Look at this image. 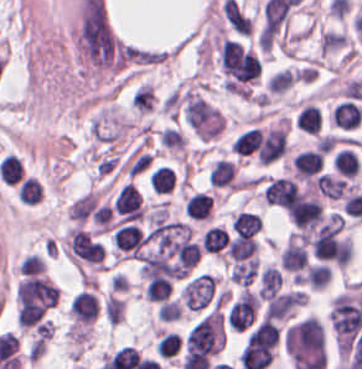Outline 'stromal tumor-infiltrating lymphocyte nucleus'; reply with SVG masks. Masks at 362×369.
<instances>
[{"instance_id":"obj_19","label":"stromal tumor-infiltrating lymphocyte nucleus","mask_w":362,"mask_h":369,"mask_svg":"<svg viewBox=\"0 0 362 369\" xmlns=\"http://www.w3.org/2000/svg\"><path fill=\"white\" fill-rule=\"evenodd\" d=\"M331 277L330 267L324 263L309 266L305 275L306 284L310 289L320 290L325 287Z\"/></svg>"},{"instance_id":"obj_18","label":"stromal tumor-infiltrating lymphocyte nucleus","mask_w":362,"mask_h":369,"mask_svg":"<svg viewBox=\"0 0 362 369\" xmlns=\"http://www.w3.org/2000/svg\"><path fill=\"white\" fill-rule=\"evenodd\" d=\"M174 181L171 169L166 166H159L149 179L151 190L161 195L171 190Z\"/></svg>"},{"instance_id":"obj_10","label":"stromal tumor-infiltrating lymphocyte nucleus","mask_w":362,"mask_h":369,"mask_svg":"<svg viewBox=\"0 0 362 369\" xmlns=\"http://www.w3.org/2000/svg\"><path fill=\"white\" fill-rule=\"evenodd\" d=\"M331 164L335 173L354 177L359 171L358 157L356 152L349 147H342L332 158Z\"/></svg>"},{"instance_id":"obj_9","label":"stromal tumor-infiltrating lymphocyte nucleus","mask_w":362,"mask_h":369,"mask_svg":"<svg viewBox=\"0 0 362 369\" xmlns=\"http://www.w3.org/2000/svg\"><path fill=\"white\" fill-rule=\"evenodd\" d=\"M228 234L227 231L219 227L212 226L207 228L200 240L202 252L213 256H221L227 247Z\"/></svg>"},{"instance_id":"obj_5","label":"stromal tumor-infiltrating lymphocyte nucleus","mask_w":362,"mask_h":369,"mask_svg":"<svg viewBox=\"0 0 362 369\" xmlns=\"http://www.w3.org/2000/svg\"><path fill=\"white\" fill-rule=\"evenodd\" d=\"M290 167L294 177L312 178L322 169L321 156L317 149H304L294 154Z\"/></svg>"},{"instance_id":"obj_3","label":"stromal tumor-infiltrating lymphocyte nucleus","mask_w":362,"mask_h":369,"mask_svg":"<svg viewBox=\"0 0 362 369\" xmlns=\"http://www.w3.org/2000/svg\"><path fill=\"white\" fill-rule=\"evenodd\" d=\"M208 185L213 188L238 189L237 164L218 159L208 171Z\"/></svg>"},{"instance_id":"obj_8","label":"stromal tumor-infiltrating lymphocyte nucleus","mask_w":362,"mask_h":369,"mask_svg":"<svg viewBox=\"0 0 362 369\" xmlns=\"http://www.w3.org/2000/svg\"><path fill=\"white\" fill-rule=\"evenodd\" d=\"M281 275L273 265H265L258 276V298L269 300L278 293Z\"/></svg>"},{"instance_id":"obj_13","label":"stromal tumor-infiltrating lymphocyte nucleus","mask_w":362,"mask_h":369,"mask_svg":"<svg viewBox=\"0 0 362 369\" xmlns=\"http://www.w3.org/2000/svg\"><path fill=\"white\" fill-rule=\"evenodd\" d=\"M258 248L259 245L253 238L237 236L229 240L226 253L229 258L238 262L253 256Z\"/></svg>"},{"instance_id":"obj_1","label":"stromal tumor-infiltrating lymphocyte nucleus","mask_w":362,"mask_h":369,"mask_svg":"<svg viewBox=\"0 0 362 369\" xmlns=\"http://www.w3.org/2000/svg\"><path fill=\"white\" fill-rule=\"evenodd\" d=\"M145 242L142 232L134 224H120L110 235V243L114 249L125 256L134 258Z\"/></svg>"},{"instance_id":"obj_16","label":"stromal tumor-infiltrating lymphocyte nucleus","mask_w":362,"mask_h":369,"mask_svg":"<svg viewBox=\"0 0 362 369\" xmlns=\"http://www.w3.org/2000/svg\"><path fill=\"white\" fill-rule=\"evenodd\" d=\"M171 294V282L163 277H150L145 288V301L162 302Z\"/></svg>"},{"instance_id":"obj_7","label":"stromal tumor-infiltrating lymphocyte nucleus","mask_w":362,"mask_h":369,"mask_svg":"<svg viewBox=\"0 0 362 369\" xmlns=\"http://www.w3.org/2000/svg\"><path fill=\"white\" fill-rule=\"evenodd\" d=\"M184 212L191 219L209 220L212 213L211 194L196 192L185 201Z\"/></svg>"},{"instance_id":"obj_4","label":"stromal tumor-infiltrating lymphocyte nucleus","mask_w":362,"mask_h":369,"mask_svg":"<svg viewBox=\"0 0 362 369\" xmlns=\"http://www.w3.org/2000/svg\"><path fill=\"white\" fill-rule=\"evenodd\" d=\"M279 261L286 272L297 273L304 270L307 256L302 243L288 236L280 251Z\"/></svg>"},{"instance_id":"obj_17","label":"stromal tumor-infiltrating lymphocyte nucleus","mask_w":362,"mask_h":369,"mask_svg":"<svg viewBox=\"0 0 362 369\" xmlns=\"http://www.w3.org/2000/svg\"><path fill=\"white\" fill-rule=\"evenodd\" d=\"M260 130L261 128L254 126L237 136L231 145L233 153L241 154L246 157L253 153L256 148Z\"/></svg>"},{"instance_id":"obj_12","label":"stromal tumor-infiltrating lymphocyte nucleus","mask_w":362,"mask_h":369,"mask_svg":"<svg viewBox=\"0 0 362 369\" xmlns=\"http://www.w3.org/2000/svg\"><path fill=\"white\" fill-rule=\"evenodd\" d=\"M260 219L249 211H239L231 215V226L234 235L253 236L262 227Z\"/></svg>"},{"instance_id":"obj_2","label":"stromal tumor-infiltrating lymphocyte nucleus","mask_w":362,"mask_h":369,"mask_svg":"<svg viewBox=\"0 0 362 369\" xmlns=\"http://www.w3.org/2000/svg\"><path fill=\"white\" fill-rule=\"evenodd\" d=\"M112 210L126 221H139L142 217L141 198L130 184H123L113 202Z\"/></svg>"},{"instance_id":"obj_6","label":"stromal tumor-infiltrating lymphocyte nucleus","mask_w":362,"mask_h":369,"mask_svg":"<svg viewBox=\"0 0 362 369\" xmlns=\"http://www.w3.org/2000/svg\"><path fill=\"white\" fill-rule=\"evenodd\" d=\"M330 124L343 129H354L359 124V109L351 99H343L331 108Z\"/></svg>"},{"instance_id":"obj_11","label":"stromal tumor-infiltrating lymphocyte nucleus","mask_w":362,"mask_h":369,"mask_svg":"<svg viewBox=\"0 0 362 369\" xmlns=\"http://www.w3.org/2000/svg\"><path fill=\"white\" fill-rule=\"evenodd\" d=\"M258 257H250L233 265L228 273L232 283L239 286H248L258 271Z\"/></svg>"},{"instance_id":"obj_14","label":"stromal tumor-infiltrating lymphocyte nucleus","mask_w":362,"mask_h":369,"mask_svg":"<svg viewBox=\"0 0 362 369\" xmlns=\"http://www.w3.org/2000/svg\"><path fill=\"white\" fill-rule=\"evenodd\" d=\"M295 128L317 134L321 124L320 110L312 104H305L294 119Z\"/></svg>"},{"instance_id":"obj_15","label":"stromal tumor-infiltrating lymphocyte nucleus","mask_w":362,"mask_h":369,"mask_svg":"<svg viewBox=\"0 0 362 369\" xmlns=\"http://www.w3.org/2000/svg\"><path fill=\"white\" fill-rule=\"evenodd\" d=\"M296 79L297 76L291 68H284L271 73L264 84V88L265 90L280 95L288 89Z\"/></svg>"}]
</instances>
